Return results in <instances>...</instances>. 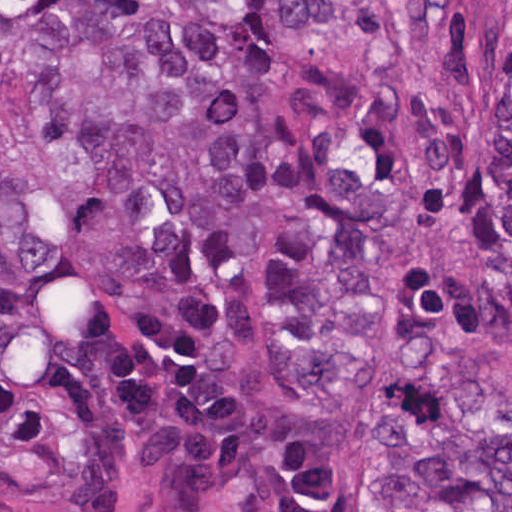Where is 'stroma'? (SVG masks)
I'll return each instance as SVG.
<instances>
[{
    "instance_id": "1",
    "label": "stroma",
    "mask_w": 512,
    "mask_h": 512,
    "mask_svg": "<svg viewBox=\"0 0 512 512\" xmlns=\"http://www.w3.org/2000/svg\"><path fill=\"white\" fill-rule=\"evenodd\" d=\"M488 71V119L485 135L472 165L471 176L461 195L423 231L397 269L390 299L380 317L377 337L369 360V393L363 417V467L360 503L364 495V451L375 422L388 405L398 375L385 361L382 344L391 315L407 304L422 260L432 254L467 246L464 222L470 190L481 173L493 140V63L506 29L512 30V0H473ZM0 512H1V0H0Z\"/></svg>"
}]
</instances>
